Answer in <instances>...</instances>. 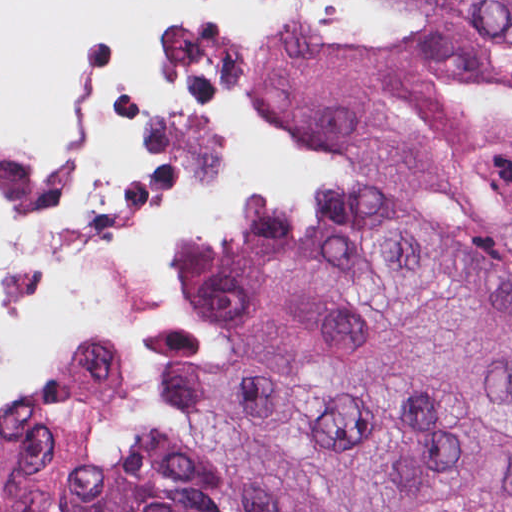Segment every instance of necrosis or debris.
Returning a JSON list of instances; mask_svg holds the SVG:
<instances>
[{
	"label": "necrosis or debris",
	"instance_id": "necrosis-or-debris-1",
	"mask_svg": "<svg viewBox=\"0 0 512 512\" xmlns=\"http://www.w3.org/2000/svg\"><path fill=\"white\" fill-rule=\"evenodd\" d=\"M57 2V46L0 84V393L68 351L120 416L192 240L322 178L261 103L263 69L380 39L390 0Z\"/></svg>",
	"mask_w": 512,
	"mask_h": 512
}]
</instances>
